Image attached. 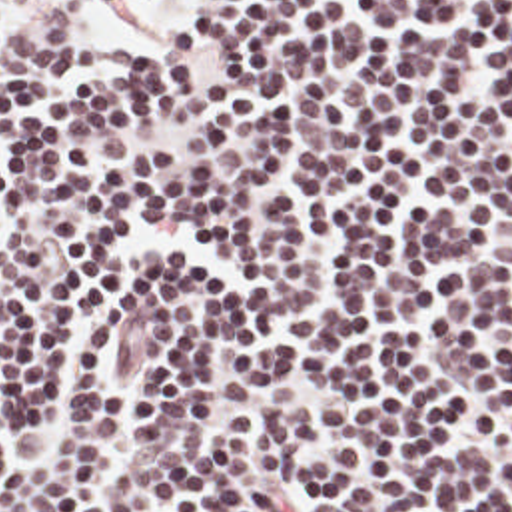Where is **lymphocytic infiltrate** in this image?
Here are the masks:
<instances>
[{
  "mask_svg": "<svg viewBox=\"0 0 512 512\" xmlns=\"http://www.w3.org/2000/svg\"><path fill=\"white\" fill-rule=\"evenodd\" d=\"M85 2L0 6V512H512V0Z\"/></svg>",
  "mask_w": 512,
  "mask_h": 512,
  "instance_id": "lymphocytic-infiltrate-1",
  "label": "lymphocytic infiltrate"
}]
</instances>
